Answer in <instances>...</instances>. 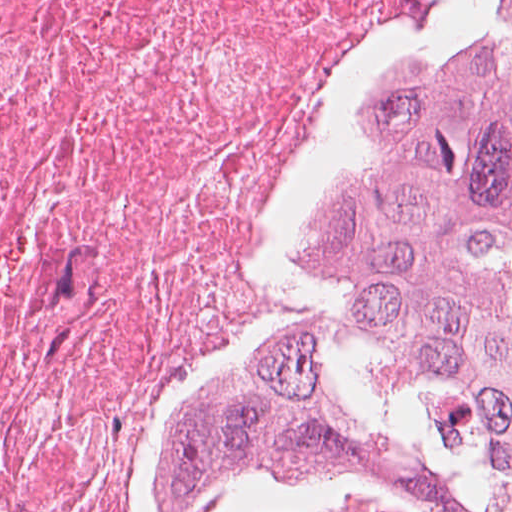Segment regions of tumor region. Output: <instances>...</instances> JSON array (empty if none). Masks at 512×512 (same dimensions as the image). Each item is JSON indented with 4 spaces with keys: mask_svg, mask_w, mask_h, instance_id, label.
Segmentation results:
<instances>
[{
    "mask_svg": "<svg viewBox=\"0 0 512 512\" xmlns=\"http://www.w3.org/2000/svg\"><path fill=\"white\" fill-rule=\"evenodd\" d=\"M403 38L328 139L278 290L149 445L139 512H512V0H418Z\"/></svg>",
    "mask_w": 512,
    "mask_h": 512,
    "instance_id": "e687c5a6",
    "label": "tumor region"
}]
</instances>
